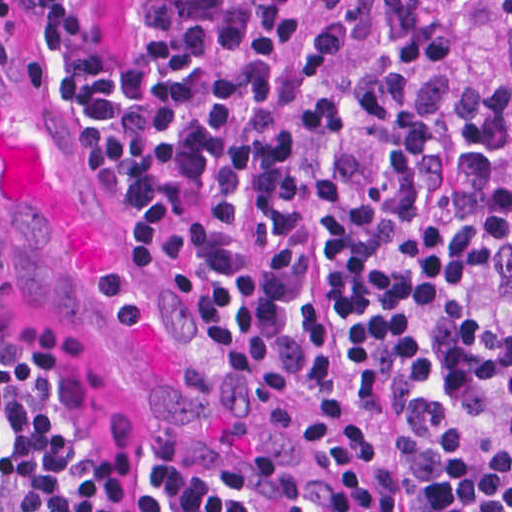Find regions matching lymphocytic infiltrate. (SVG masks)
<instances>
[{
  "label": "lymphocytic infiltrate",
  "instance_id": "obj_1",
  "mask_svg": "<svg viewBox=\"0 0 512 512\" xmlns=\"http://www.w3.org/2000/svg\"><path fill=\"white\" fill-rule=\"evenodd\" d=\"M104 139L100 194L351 512H512V90L437 0H24ZM512 8V0H503ZM12 0H0L10 23ZM0 512H245L114 459L0 319Z\"/></svg>",
  "mask_w": 512,
  "mask_h": 512
}]
</instances>
